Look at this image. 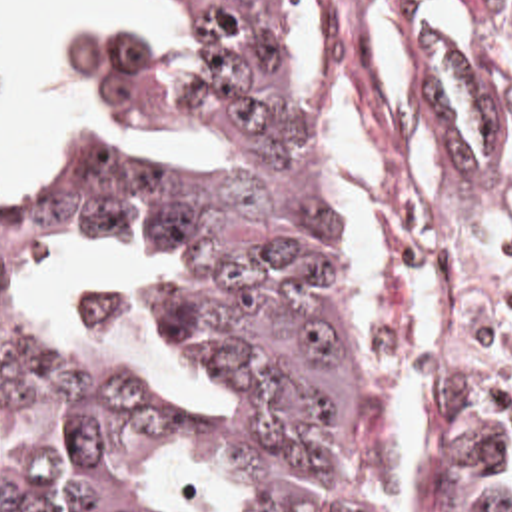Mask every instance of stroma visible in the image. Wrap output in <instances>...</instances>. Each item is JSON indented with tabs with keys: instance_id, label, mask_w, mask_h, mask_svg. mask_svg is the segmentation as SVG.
Masks as SVG:
<instances>
[{
	"instance_id": "obj_1",
	"label": "stroma",
	"mask_w": 512,
	"mask_h": 512,
	"mask_svg": "<svg viewBox=\"0 0 512 512\" xmlns=\"http://www.w3.org/2000/svg\"><path fill=\"white\" fill-rule=\"evenodd\" d=\"M476 0H464L466 6ZM288 38V96L300 132V176L306 196H324L314 172L318 108L302 80L290 28V2L284 0ZM84 30L132 32L168 56L182 50L190 26L172 0L168 22H70L54 34V54L80 82L76 126H46L20 146L16 166L0 174V196L22 180L24 168L40 146H64L126 164L206 170L212 144L202 136L150 138L134 128L106 98L98 82L74 60L72 38ZM424 56L418 62V94L424 130L438 156V176L426 198L414 194L406 174V152L378 78L356 40L344 42L342 78L364 122L374 150L406 202L418 214L438 256V320L442 364L432 400L410 406L420 410V436L410 464V512H420L432 468L438 430L446 412L462 398H472L512 412V182L468 162L452 150L436 128L424 86ZM406 328V284L392 280L378 326L364 328L370 364L378 376L390 416L400 402L392 390Z\"/></svg>"
}]
</instances>
